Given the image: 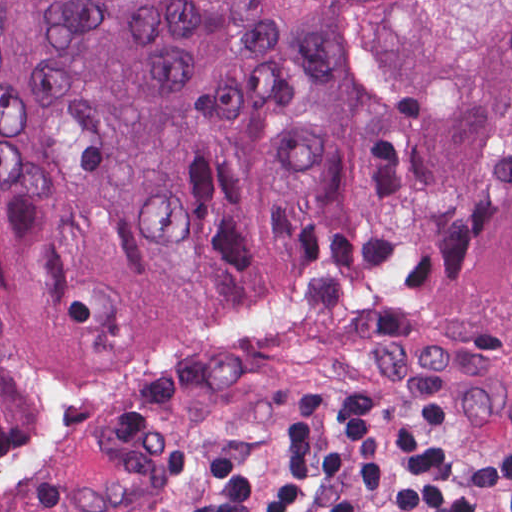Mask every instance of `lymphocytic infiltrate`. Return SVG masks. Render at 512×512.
Returning <instances> with one entry per match:
<instances>
[{"mask_svg": "<svg viewBox=\"0 0 512 512\" xmlns=\"http://www.w3.org/2000/svg\"><path fill=\"white\" fill-rule=\"evenodd\" d=\"M177 512H512V428L455 410H286Z\"/></svg>", "mask_w": 512, "mask_h": 512, "instance_id": "obj_1", "label": "lymphocytic infiltrate"}]
</instances>
